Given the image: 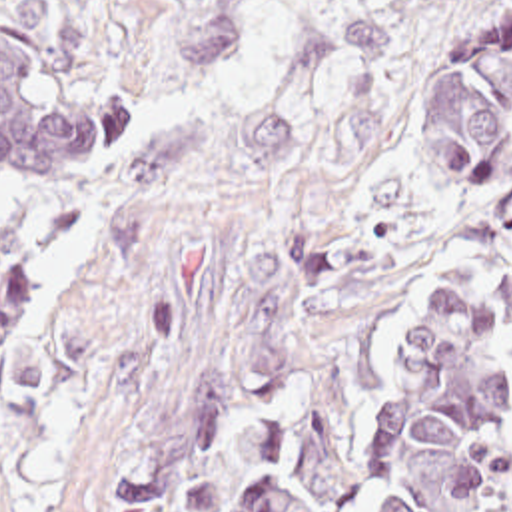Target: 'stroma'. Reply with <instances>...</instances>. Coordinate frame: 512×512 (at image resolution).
Masks as SVG:
<instances>
[{"mask_svg": "<svg viewBox=\"0 0 512 512\" xmlns=\"http://www.w3.org/2000/svg\"><path fill=\"white\" fill-rule=\"evenodd\" d=\"M46 71L122 107L96 181L0 179L38 265L0 369V512H140L210 415L433 281L493 309L512 411L511 141L481 199L415 165L421 0H0Z\"/></svg>", "mask_w": 512, "mask_h": 512, "instance_id": "stroma-1", "label": "stroma"}]
</instances>
